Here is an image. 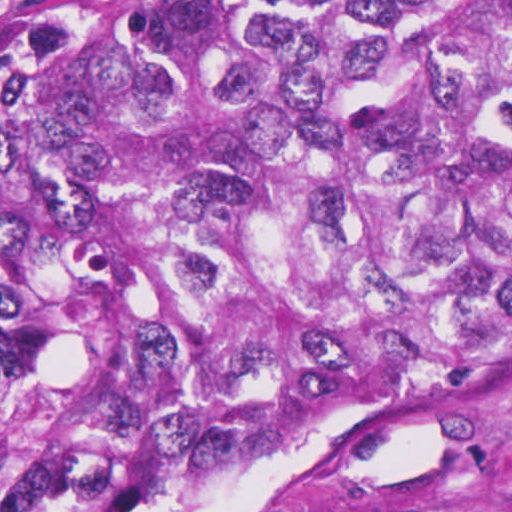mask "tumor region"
I'll use <instances>...</instances> for the list:
<instances>
[{
  "label": "tumor region",
  "mask_w": 512,
  "mask_h": 512,
  "mask_svg": "<svg viewBox=\"0 0 512 512\" xmlns=\"http://www.w3.org/2000/svg\"><path fill=\"white\" fill-rule=\"evenodd\" d=\"M512 361V0H62L0 35V512Z\"/></svg>",
  "instance_id": "tumor-region-1"
}]
</instances>
